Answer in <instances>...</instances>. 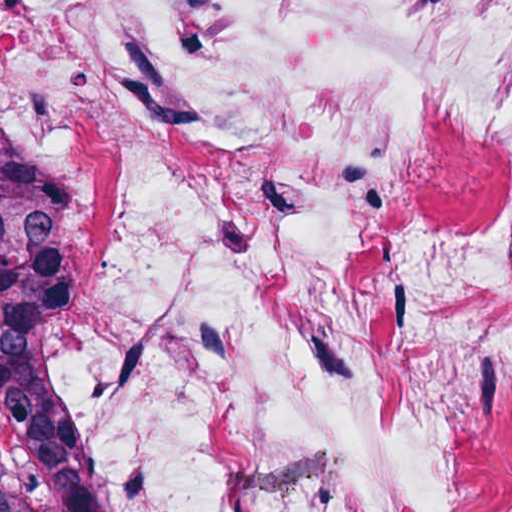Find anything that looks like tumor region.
I'll return each mask as SVG.
<instances>
[{
	"label": "tumor region",
	"instance_id": "e687c5a6",
	"mask_svg": "<svg viewBox=\"0 0 512 512\" xmlns=\"http://www.w3.org/2000/svg\"><path fill=\"white\" fill-rule=\"evenodd\" d=\"M70 228L63 176L0 103V512H83L86 464L37 364Z\"/></svg>",
	"mask_w": 512,
	"mask_h": 512
}]
</instances>
